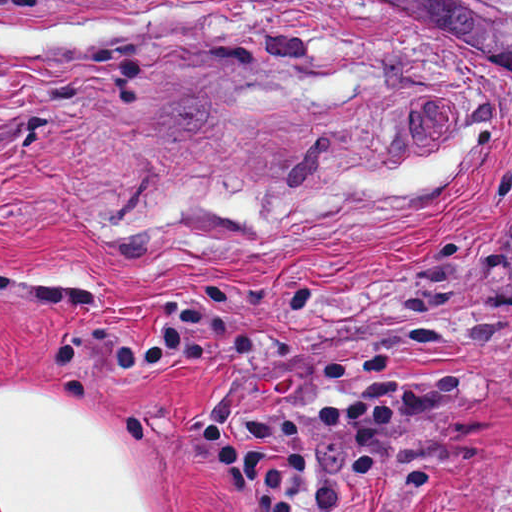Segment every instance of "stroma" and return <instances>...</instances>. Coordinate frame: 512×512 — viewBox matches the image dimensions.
<instances>
[{"label":"stroma","mask_w":512,"mask_h":512,"mask_svg":"<svg viewBox=\"0 0 512 512\" xmlns=\"http://www.w3.org/2000/svg\"><path fill=\"white\" fill-rule=\"evenodd\" d=\"M52 373L169 512H489L512 62L346 0H0V386Z\"/></svg>","instance_id":"35a3bbf8"}]
</instances>
